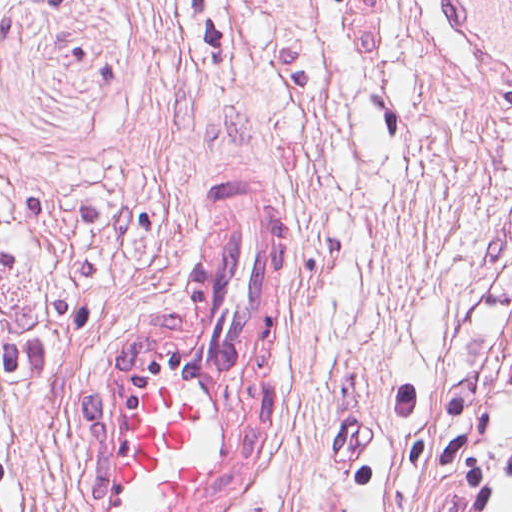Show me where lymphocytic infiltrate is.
<instances>
[{
	"label": "lymphocytic infiltrate",
	"instance_id": "lymphocytic-infiltrate-1",
	"mask_svg": "<svg viewBox=\"0 0 512 512\" xmlns=\"http://www.w3.org/2000/svg\"><path fill=\"white\" fill-rule=\"evenodd\" d=\"M32 240L28 196L0 168V297ZM50 343L0 322V499L18 457L12 388L35 393L58 382ZM405 452L439 482L446 512L512 506V349L464 377L406 385L396 412Z\"/></svg>",
	"mask_w": 512,
	"mask_h": 512
}]
</instances>
